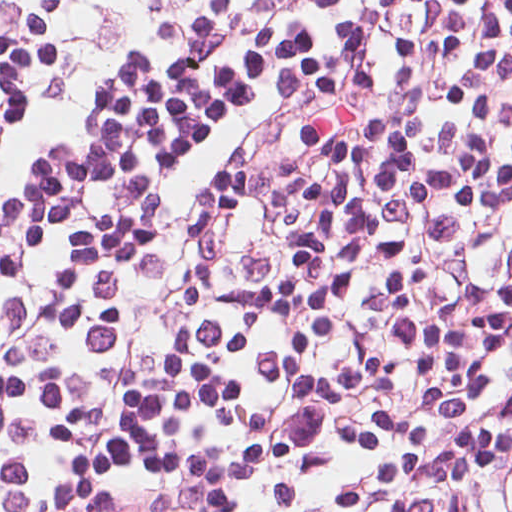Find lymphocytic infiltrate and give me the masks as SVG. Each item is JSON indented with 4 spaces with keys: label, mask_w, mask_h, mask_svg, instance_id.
<instances>
[{
    "label": "lymphocytic infiltrate",
    "mask_w": 512,
    "mask_h": 512,
    "mask_svg": "<svg viewBox=\"0 0 512 512\" xmlns=\"http://www.w3.org/2000/svg\"><path fill=\"white\" fill-rule=\"evenodd\" d=\"M0 512H512V0H0Z\"/></svg>",
    "instance_id": "lymphocytic-infiltrate-1"
}]
</instances>
